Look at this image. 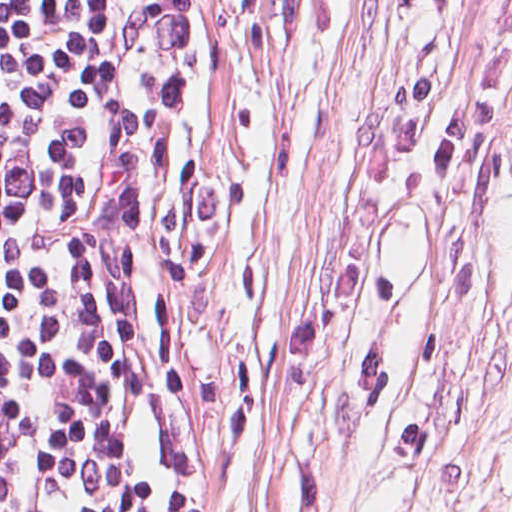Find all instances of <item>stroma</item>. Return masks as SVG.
<instances>
[{
  "label": "stroma",
  "mask_w": 512,
  "mask_h": 512,
  "mask_svg": "<svg viewBox=\"0 0 512 512\" xmlns=\"http://www.w3.org/2000/svg\"><path fill=\"white\" fill-rule=\"evenodd\" d=\"M512 0H168L136 512H512Z\"/></svg>",
  "instance_id": "1"
}]
</instances>
